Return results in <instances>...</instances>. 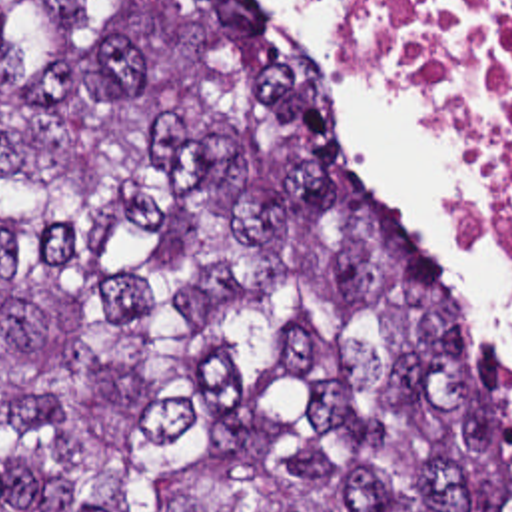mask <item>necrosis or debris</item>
Returning a JSON list of instances; mask_svg holds the SVG:
<instances>
[{
  "instance_id": "necrosis-or-debris-1",
  "label": "necrosis or debris",
  "mask_w": 512,
  "mask_h": 512,
  "mask_svg": "<svg viewBox=\"0 0 512 512\" xmlns=\"http://www.w3.org/2000/svg\"><path fill=\"white\" fill-rule=\"evenodd\" d=\"M349 63L397 77L476 157L484 183L464 215L490 247L512 229V0H331Z\"/></svg>"
}]
</instances>
